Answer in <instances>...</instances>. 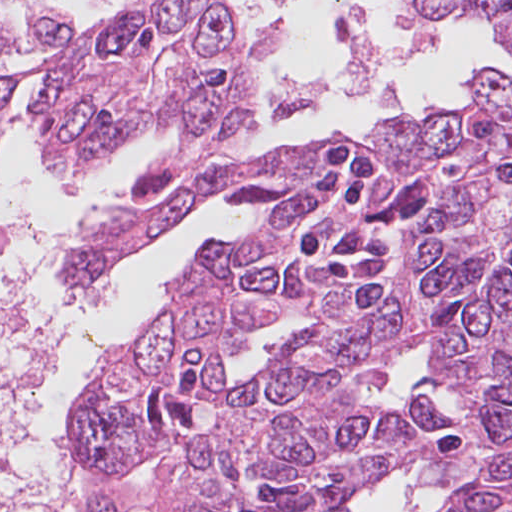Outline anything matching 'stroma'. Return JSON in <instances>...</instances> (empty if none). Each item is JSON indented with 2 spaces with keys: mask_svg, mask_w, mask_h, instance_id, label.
Here are the masks:
<instances>
[{
  "mask_svg": "<svg viewBox=\"0 0 512 512\" xmlns=\"http://www.w3.org/2000/svg\"><path fill=\"white\" fill-rule=\"evenodd\" d=\"M510 17H512V13H510L508 15H505V16L499 18V19L489 20V21H484V22H479V23H493V22L502 21V20L510 18ZM471 105H472V103L470 105H468V106H471ZM468 106H466V107H468ZM10 110H11V107H10ZM254 118H255V102H254V112H253V116L251 118V128H252V125L254 123ZM386 118H414V119L422 120V118H423V111H422L420 117L404 115V114H394V115H391V116H383V117L377 119L375 121V123L380 121V120H382V119H386ZM372 127L367 130L363 140L360 142L361 144H363L366 147L371 145L367 135L371 131ZM334 133H343V134L348 135L347 133L341 132V131H336ZM329 134H331V133H329ZM329 134H324V135L312 137V138H309V139H306V140H303V141L294 142V143L288 144V145H283L281 147H268L266 149H251V147L249 145L248 148H247V152H248L249 156H252V155L263 154V153H268V152H273V151H279V150L288 149V148H294V147H298L300 145L312 143L317 138L324 137V136L329 135ZM163 136H171V137L176 138L177 141H178V135L175 132H167V133H163L161 135H150V136L146 137L145 139H143L141 142H139L137 145L133 146L128 151L123 153L120 158L125 157L130 152H132L134 149L143 146L146 141L155 140V139L163 137ZM36 141H37L38 148L43 153V151H42V149L40 147V141L38 139V135L37 134H36ZM170 158L160 162L159 164L165 163ZM135 196H136V198H139V199H146V198H151V197L156 196L157 204L155 206L159 205L167 197V195L166 196H160L156 192L151 194L149 197L141 195L139 193V180H138L137 185H136ZM221 196H224L222 192L217 197H221ZM217 197H215V198H217ZM236 203L239 205V207L241 208L242 212L244 213V215H245V217L247 219V235H248V228H249V226L252 223V211H251V209H250L248 204H246L244 202H236ZM138 209H142V208L126 206V207H121V208H118L116 210L110 211V212L100 216L95 221L85 225L80 230H78L76 233L71 235L68 238V240L64 243V245L62 246V248L60 250V253H59V263H58V266H57L59 284L62 287H64L62 285L61 281H60V271H61V268L63 267V265L67 262V260L72 255V249H73L74 245L77 243V241L84 234L90 232V230L92 229L93 226H95V225L99 224L100 222H102L103 220H105L107 218V216L109 214H111V213H114L116 211H132V210H138ZM165 235H163V236H165ZM162 237H160L159 239L155 240L153 243H151L149 246H147L142 251H140V252L134 254L133 256H131L129 259H127L125 262H123L118 268L108 272L105 276H103L98 281H96L94 283H91V284H88V285H85V286H82V287L74 288V289L88 288V287H93V286H96V285L100 284L102 281H104L106 278H108L115 270H117V269H119V268L129 264L130 262L135 260L140 254H142V253L146 252L147 250H149ZM198 253L196 255H194L192 258H190L185 264H183L179 268L175 269L174 271L168 273L161 280L160 289L162 291V301H161L160 307L157 309V311L154 314L153 318L146 325V327L143 329V331L147 328V326L156 317V315L160 311V308L163 306V304L167 300V293H166L164 284L166 282H168L180 270H182L184 267L189 265L195 259V257L198 255ZM433 356H434V350L432 349L431 346H429V345H427L425 343L418 344V345L414 346L410 351H408L404 355H402L399 358L394 360V362L391 365L389 379H388L386 384H384L382 386H371L370 388L367 389V392H368V395H369L370 399L372 401H374L376 404H378V405H380V406H382L384 408L398 409V408H400V407H402L404 405V402L406 401L408 396L414 391L415 387L425 377L434 376V377L442 380L446 387L442 391H440L438 393H434V394H431V392H430V390L428 388L422 387V388H419V390L417 391L419 396L427 398V399L435 402L437 405H439L442 408L443 412L450 413V414L454 415L458 419V422H459V394L455 390H453L451 388L449 382H447L445 379H443V378H441V377H439V376H437L434 373L429 371L428 365H429L430 361L432 360ZM408 421L420 433H422L433 445H435L437 447H439L440 444H442V443L446 442L447 440H449L452 437V435L458 430V427H457L453 432H451L449 434H432V433L428 432L423 426H421L418 423L417 420H408ZM417 461H420V460H417ZM436 461H437V458L435 459V462ZM466 479H469V482H470L472 480V474L469 473V472H466V471H462V472H460V474L458 476L452 478L451 481L449 483H447V484H452V483H454L456 481L466 480ZM366 482H368V481H366ZM364 484L360 487V489L358 491L362 490ZM441 486H430V488H438V487H441ZM132 493H134L137 496L141 497L142 499L146 500L149 503V505L153 508V510L155 512H158L156 507H155V505H154V503H153V501L151 499H149L147 496H145V495H143L141 493H138L136 491H132ZM345 508L347 509L348 505H346Z\"/></svg>",
  "mask_w": 512,
  "mask_h": 512,
  "instance_id": "obj_1",
  "label": "stroma"
}]
</instances>
